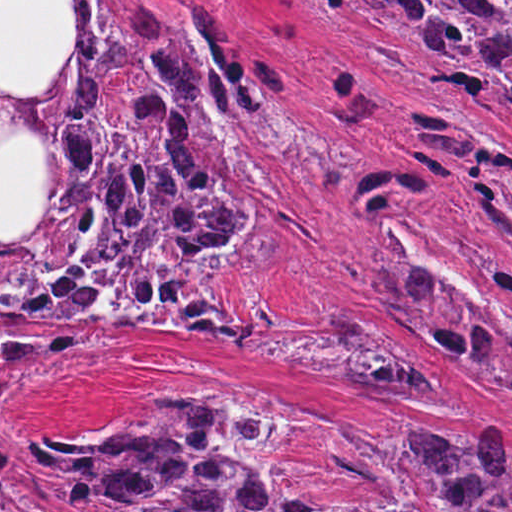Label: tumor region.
Listing matches in <instances>:
<instances>
[{"mask_svg": "<svg viewBox=\"0 0 512 512\" xmlns=\"http://www.w3.org/2000/svg\"><path fill=\"white\" fill-rule=\"evenodd\" d=\"M410 82L484 74L512 101V1H332ZM68 1V44L32 93L0 90V368L91 336L38 324L148 327L243 359H281L355 386L442 395L411 348L384 347L331 305H229L233 270L279 262L265 217L288 151L311 139L295 97L254 90L211 39L156 18L125 34ZM512 247V200L474 207ZM490 270L512 295V268ZM478 387L512 401V325L383 240V314ZM0 512H512L503 429L470 445L434 429L357 458L226 397L149 404L0 455Z\"/></svg>", "mask_w": 512, "mask_h": 512, "instance_id": "e687c5a6", "label": "tumor region"}]
</instances>
